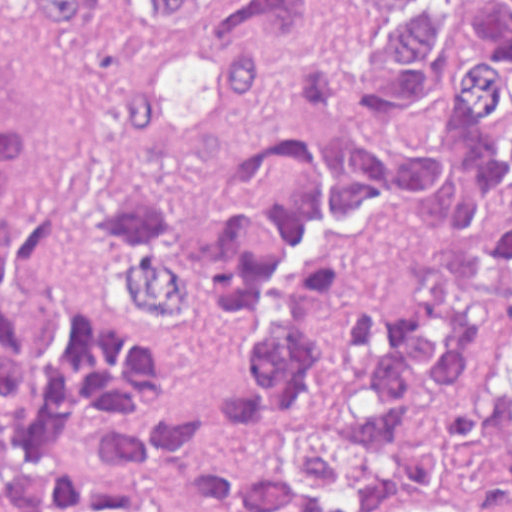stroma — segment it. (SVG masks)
Masks as SVG:
<instances>
[{
  "mask_svg": "<svg viewBox=\"0 0 512 512\" xmlns=\"http://www.w3.org/2000/svg\"><path fill=\"white\" fill-rule=\"evenodd\" d=\"M187 32H147L120 4L100 12L90 31L70 40L44 28L37 0H0V89L23 116L26 160L19 194L5 207H57L82 232V279L109 320L165 352L167 373L127 406L192 404L226 380L244 341L223 331L211 310L172 314L132 296L119 272L107 208V180L133 173L175 210L215 211L246 155L283 133L310 125L353 129L356 110L318 108L298 97L276 60L257 95L218 110L208 129L170 144L127 138L115 97L141 61L196 47ZM512 353V295L496 303L470 352L460 399L429 415L416 431L450 422L496 385ZM99 419L76 435L79 457L125 494L181 512H292L282 507H217L179 496L151 475L106 455ZM386 512H512L502 479L463 472L420 483Z\"/></svg>",
  "mask_w": 512,
  "mask_h": 512,
  "instance_id": "1",
  "label": "stroma"
}]
</instances>
